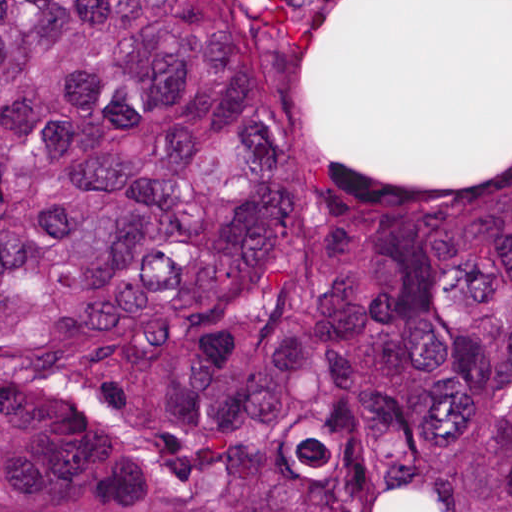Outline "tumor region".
<instances>
[{"mask_svg": "<svg viewBox=\"0 0 512 512\" xmlns=\"http://www.w3.org/2000/svg\"><path fill=\"white\" fill-rule=\"evenodd\" d=\"M0 512H512V133L307 152L243 1H0Z\"/></svg>", "mask_w": 512, "mask_h": 512, "instance_id": "1", "label": "tumor region"}]
</instances>
